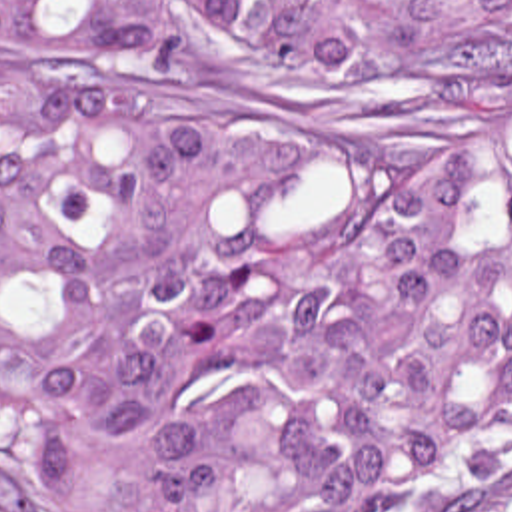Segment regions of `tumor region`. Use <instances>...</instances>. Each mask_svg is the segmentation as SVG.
<instances>
[{
    "label": "tumor region",
    "instance_id": "obj_1",
    "mask_svg": "<svg viewBox=\"0 0 512 512\" xmlns=\"http://www.w3.org/2000/svg\"><path fill=\"white\" fill-rule=\"evenodd\" d=\"M12 512H512V0H0Z\"/></svg>",
    "mask_w": 512,
    "mask_h": 512
}]
</instances>
